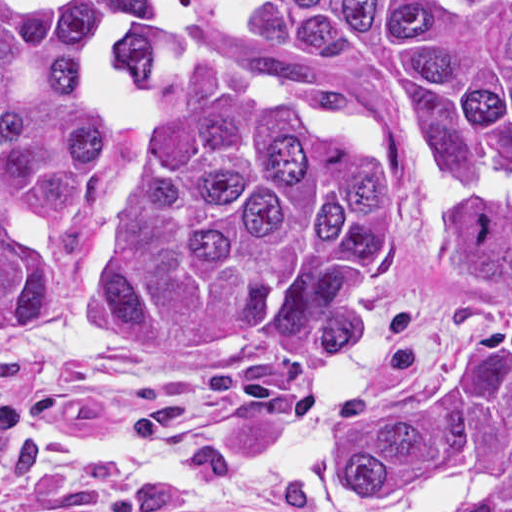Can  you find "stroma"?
I'll return each instance as SVG.
<instances>
[{"label":"stroma","instance_id":"stroma-1","mask_svg":"<svg viewBox=\"0 0 512 512\" xmlns=\"http://www.w3.org/2000/svg\"><path fill=\"white\" fill-rule=\"evenodd\" d=\"M411 235L375 298L357 360L369 390L404 384L460 334L468 303L436 252L433 225L487 180L410 174ZM63 330L58 310L16 341L0 342V409L14 425L0 469V512H68L107 493L152 484L68 454L46 451L31 431L101 439L157 438L207 423L249 455L295 434L297 414L321 375H293L252 358L209 369L124 359ZM174 512H317L295 500L214 493Z\"/></svg>","mask_w":512,"mask_h":512}]
</instances>
